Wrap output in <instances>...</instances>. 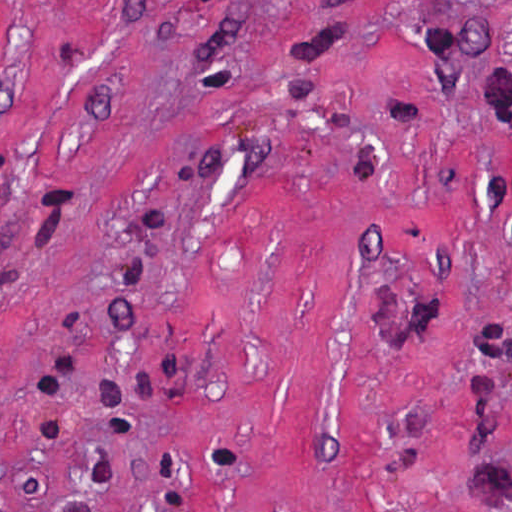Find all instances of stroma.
Masks as SVG:
<instances>
[{
	"label": "stroma",
	"mask_w": 512,
	"mask_h": 512,
	"mask_svg": "<svg viewBox=\"0 0 512 512\" xmlns=\"http://www.w3.org/2000/svg\"><path fill=\"white\" fill-rule=\"evenodd\" d=\"M0 512H512V0H0Z\"/></svg>",
	"instance_id": "stroma-1"
}]
</instances>
